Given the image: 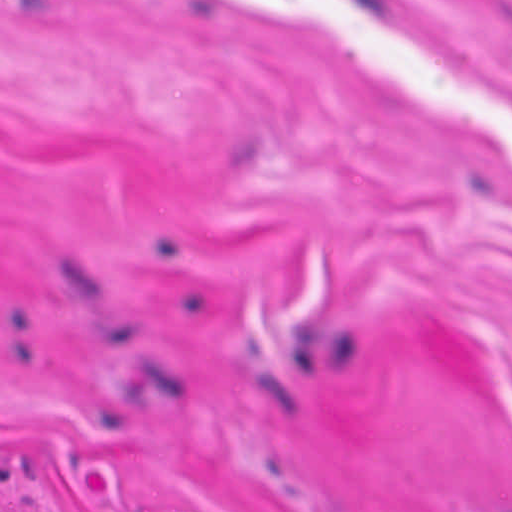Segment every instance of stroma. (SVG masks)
<instances>
[{
	"label": "stroma",
	"instance_id": "stroma-1",
	"mask_svg": "<svg viewBox=\"0 0 512 512\" xmlns=\"http://www.w3.org/2000/svg\"><path fill=\"white\" fill-rule=\"evenodd\" d=\"M0 512H512V0H0Z\"/></svg>",
	"mask_w": 512,
	"mask_h": 512
}]
</instances>
